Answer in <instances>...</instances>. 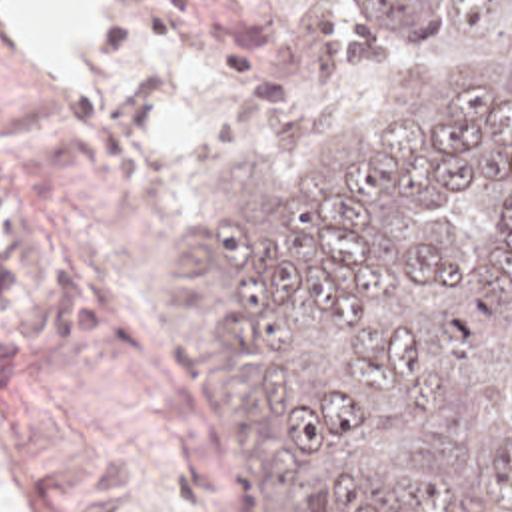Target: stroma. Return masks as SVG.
<instances>
[{
  "mask_svg": "<svg viewBox=\"0 0 512 512\" xmlns=\"http://www.w3.org/2000/svg\"><path fill=\"white\" fill-rule=\"evenodd\" d=\"M358 0H135L101 94L0 40V489L25 512H260L169 267L238 146L292 198L384 88Z\"/></svg>",
  "mask_w": 512,
  "mask_h": 512,
  "instance_id": "1",
  "label": "stroma"
}]
</instances>
